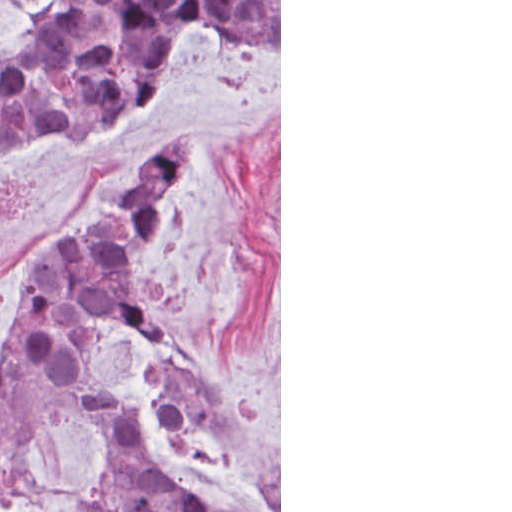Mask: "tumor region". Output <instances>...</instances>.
<instances>
[{
	"label": "tumor region",
	"instance_id": "tumor-region-1",
	"mask_svg": "<svg viewBox=\"0 0 512 512\" xmlns=\"http://www.w3.org/2000/svg\"><path fill=\"white\" fill-rule=\"evenodd\" d=\"M261 63L279 53V0H61L0 40V161L62 145L139 110L185 35ZM196 157L193 131L159 148L137 184L60 231L20 277L17 324L0 349V481L19 462L22 395L83 394L107 417L95 512H213L176 486L143 435L130 381L96 363L119 333L148 341L162 372L154 408L172 439L238 459L279 510V453L151 314L135 261L162 230L168 192Z\"/></svg>",
	"mask_w": 512,
	"mask_h": 512
}]
</instances>
